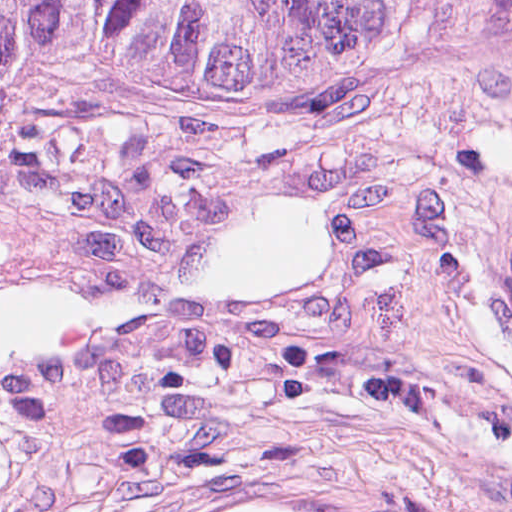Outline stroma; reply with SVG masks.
<instances>
[{"instance_id":"1","label":"stroma","mask_w":512,"mask_h":512,"mask_svg":"<svg viewBox=\"0 0 512 512\" xmlns=\"http://www.w3.org/2000/svg\"><path fill=\"white\" fill-rule=\"evenodd\" d=\"M253 485L512 512V65L343 0L169 85H0V512Z\"/></svg>"}]
</instances>
